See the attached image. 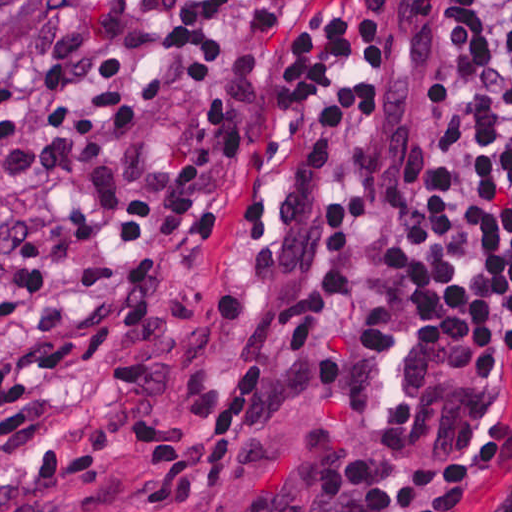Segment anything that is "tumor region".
<instances>
[{
    "label": "tumor region",
    "instance_id": "obj_1",
    "mask_svg": "<svg viewBox=\"0 0 512 512\" xmlns=\"http://www.w3.org/2000/svg\"><path fill=\"white\" fill-rule=\"evenodd\" d=\"M38 0H1V46L25 23Z\"/></svg>",
    "mask_w": 512,
    "mask_h": 512
}]
</instances>
